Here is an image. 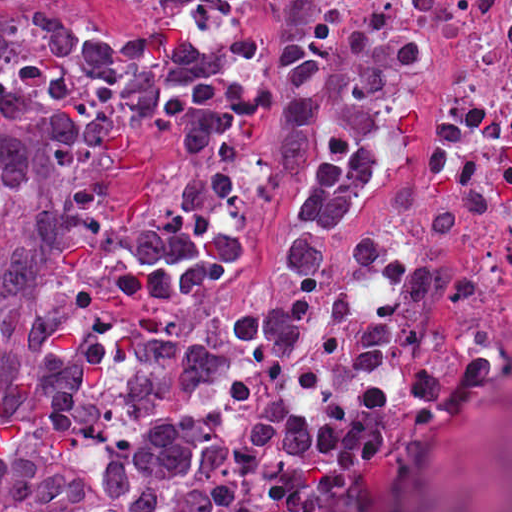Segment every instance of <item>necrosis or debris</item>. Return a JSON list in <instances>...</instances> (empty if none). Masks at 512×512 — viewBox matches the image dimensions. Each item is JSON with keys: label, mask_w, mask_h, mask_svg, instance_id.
<instances>
[{"label": "necrosis or debris", "mask_w": 512, "mask_h": 512, "mask_svg": "<svg viewBox=\"0 0 512 512\" xmlns=\"http://www.w3.org/2000/svg\"><path fill=\"white\" fill-rule=\"evenodd\" d=\"M512 22V0H203L211 87L148 130L137 187Z\"/></svg>", "instance_id": "necrosis-or-debris-1"}]
</instances>
